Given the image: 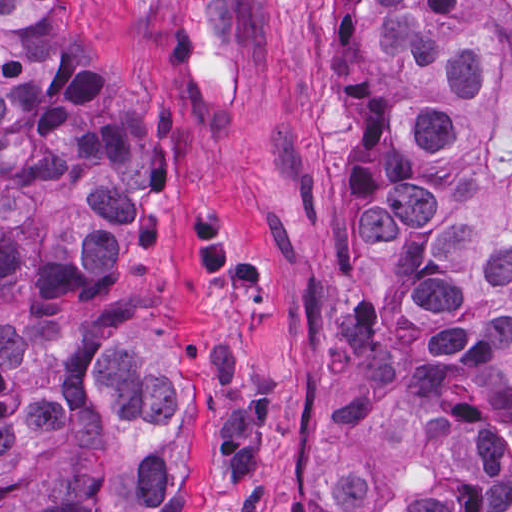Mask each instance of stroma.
<instances>
[{"label": "stroma", "mask_w": 512, "mask_h": 512, "mask_svg": "<svg viewBox=\"0 0 512 512\" xmlns=\"http://www.w3.org/2000/svg\"><path fill=\"white\" fill-rule=\"evenodd\" d=\"M136 112L124 279L191 420L189 512H325L347 309L349 133L324 0H71Z\"/></svg>", "instance_id": "1"}]
</instances>
